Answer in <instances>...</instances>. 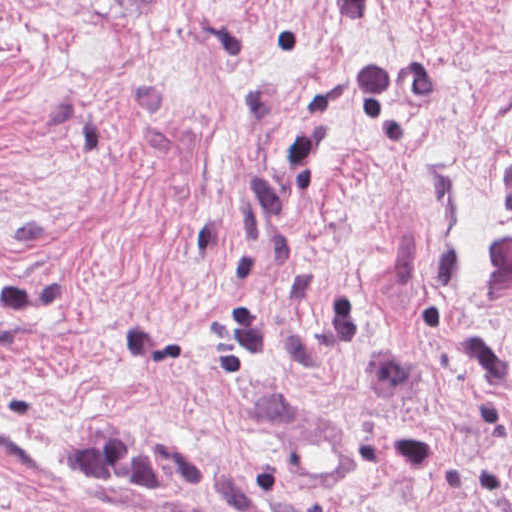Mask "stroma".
<instances>
[{"instance_id": "stroma-1", "label": "stroma", "mask_w": 512, "mask_h": 512, "mask_svg": "<svg viewBox=\"0 0 512 512\" xmlns=\"http://www.w3.org/2000/svg\"><path fill=\"white\" fill-rule=\"evenodd\" d=\"M0 512H512V0H0Z\"/></svg>"}]
</instances>
